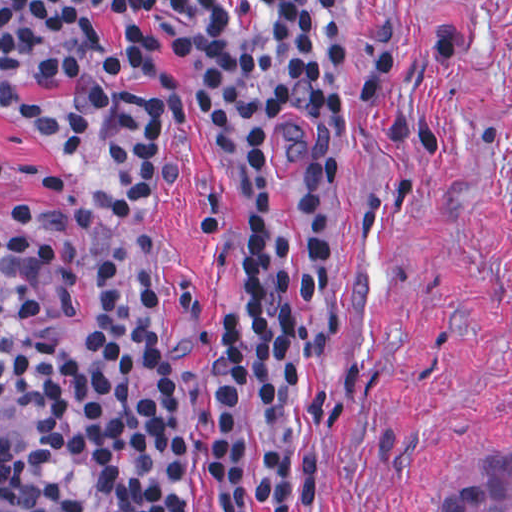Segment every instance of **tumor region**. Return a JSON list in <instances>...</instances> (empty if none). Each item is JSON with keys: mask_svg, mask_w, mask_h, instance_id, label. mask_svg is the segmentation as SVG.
Masks as SVG:
<instances>
[{"mask_svg": "<svg viewBox=\"0 0 512 512\" xmlns=\"http://www.w3.org/2000/svg\"><path fill=\"white\" fill-rule=\"evenodd\" d=\"M25 271L0 239V512H42L15 474L14 441L28 426V407L17 382L19 327L12 312L15 281ZM441 512H512V449H479L464 484Z\"/></svg>", "mask_w": 512, "mask_h": 512, "instance_id": "e687c5a6", "label": "tumor region"}]
</instances>
